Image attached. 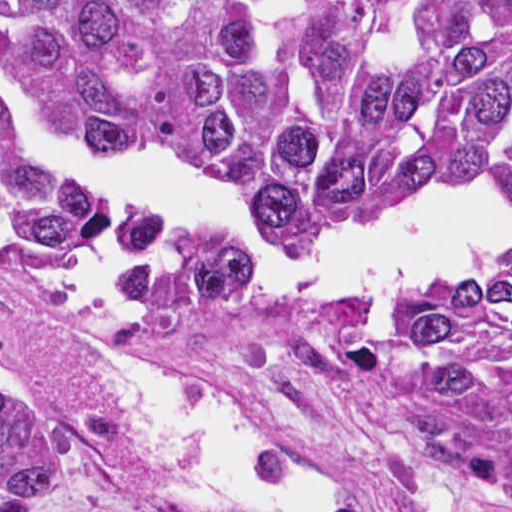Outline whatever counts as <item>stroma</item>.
<instances>
[{
  "mask_svg": "<svg viewBox=\"0 0 512 512\" xmlns=\"http://www.w3.org/2000/svg\"><path fill=\"white\" fill-rule=\"evenodd\" d=\"M45 263L0 239V395L56 436L70 456L65 501L33 512L108 503L147 472V435L131 430L75 347L100 345L225 386L303 478L346 512H435L429 453L357 392L335 358L311 350L219 366L145 322L72 306L41 279ZM166 512H242L180 498Z\"/></svg>",
  "mask_w": 512,
  "mask_h": 512,
  "instance_id": "obj_1",
  "label": "stroma"
}]
</instances>
